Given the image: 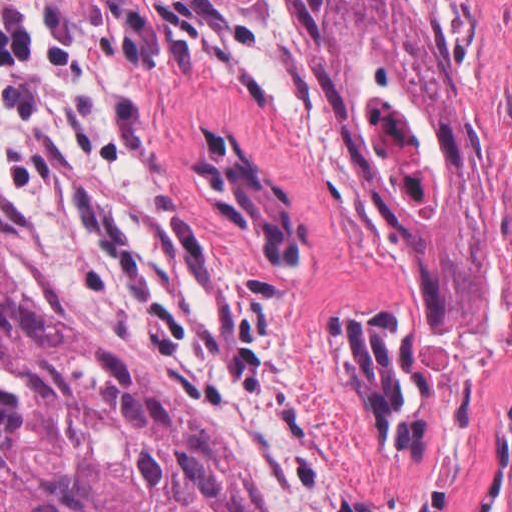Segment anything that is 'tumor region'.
Here are the masks:
<instances>
[{
    "label": "tumor region",
    "mask_w": 512,
    "mask_h": 512,
    "mask_svg": "<svg viewBox=\"0 0 512 512\" xmlns=\"http://www.w3.org/2000/svg\"><path fill=\"white\" fill-rule=\"evenodd\" d=\"M322 100L388 202L427 283L431 332L474 346L490 324V158L459 96L393 0H300ZM212 209L272 265L305 229L243 145L193 168ZM370 426L421 442L430 361L396 305L328 325ZM0 512H265L164 380L64 329L6 256L0 228Z\"/></svg>",
    "instance_id": "tumor-region-1"
}]
</instances>
